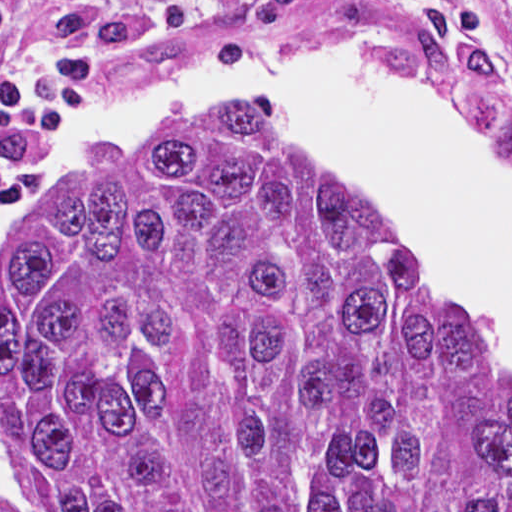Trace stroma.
Masks as SVG:
<instances>
[{"mask_svg":"<svg viewBox=\"0 0 512 512\" xmlns=\"http://www.w3.org/2000/svg\"><path fill=\"white\" fill-rule=\"evenodd\" d=\"M257 0H224L225 19L207 44L159 50L113 69L103 80L100 100L131 90H159L227 78L263 55L306 43H386L421 55L418 48L372 38L353 30L308 22L277 40L254 38L249 17ZM381 8L437 9L474 29L491 52L512 64V0H377ZM448 83V82H447ZM462 110L482 139L512 163V88L503 96L475 94L448 83ZM36 138L0 132V169L14 161Z\"/></svg>","mask_w":512,"mask_h":512,"instance_id":"obj_1","label":"stroma"}]
</instances>
